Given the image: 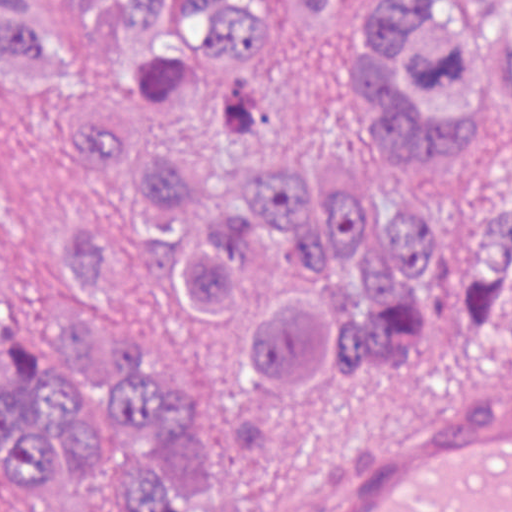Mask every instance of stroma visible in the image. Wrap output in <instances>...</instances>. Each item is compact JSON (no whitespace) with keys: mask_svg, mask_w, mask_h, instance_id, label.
Instances as JSON below:
<instances>
[{"mask_svg":"<svg viewBox=\"0 0 512 512\" xmlns=\"http://www.w3.org/2000/svg\"><path fill=\"white\" fill-rule=\"evenodd\" d=\"M93 76L66 0H31ZM255 89L322 160L365 183L449 210L512 202V130L498 155L468 173H409L373 165L345 101L301 30H274L255 49ZM102 206L82 158L59 128V103L0 79V225L18 267V307L53 329L84 299L65 287L61 220L98 228ZM141 311L153 354L180 385L212 446L224 512H273L315 467L443 412L512 377V310L492 328L409 360L340 373L331 383L273 402L229 371L188 352L156 298L96 295L88 315L112 321ZM32 332H47L20 315Z\"/></svg>","mask_w":512,"mask_h":512,"instance_id":"1","label":"stroma"}]
</instances>
